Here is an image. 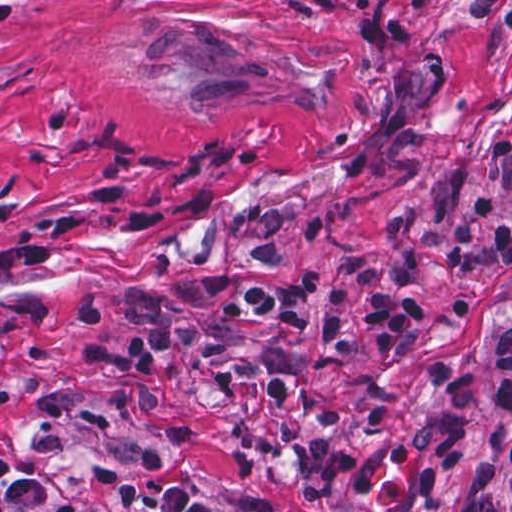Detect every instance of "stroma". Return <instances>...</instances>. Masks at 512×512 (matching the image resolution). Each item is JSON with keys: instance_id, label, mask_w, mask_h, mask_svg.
<instances>
[{"instance_id": "obj_1", "label": "stroma", "mask_w": 512, "mask_h": 512, "mask_svg": "<svg viewBox=\"0 0 512 512\" xmlns=\"http://www.w3.org/2000/svg\"><path fill=\"white\" fill-rule=\"evenodd\" d=\"M496 199L512 220V0H0V459L95 512L125 483L195 484L216 512H449L471 480L452 471L431 498L387 447L435 413L442 391L386 366L358 339L349 363L389 386L394 411L373 433L368 405L329 372L315 391L335 425L297 406L316 446H343L366 495L307 505L284 451L255 473L233 439L274 413L265 388L224 392L238 357L290 365L318 346L300 329L233 318L201 292L219 273L285 287L320 275L314 315L362 254L394 294V221L423 213L428 250L414 298L421 330L400 345L467 366L482 390L474 461L511 469L512 414L496 399L495 338L512 321V264L471 209ZM155 297L233 338L218 360L171 352L165 419L110 398L115 375L79 349L96 331L81 305L106 302L111 339L147 331L125 302ZM0 512H40L0 500Z\"/></svg>"}]
</instances>
